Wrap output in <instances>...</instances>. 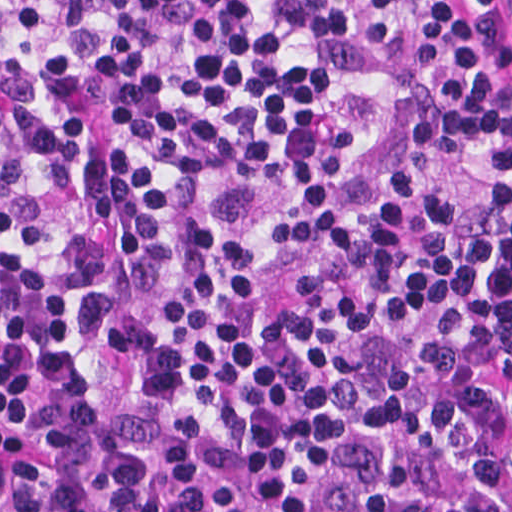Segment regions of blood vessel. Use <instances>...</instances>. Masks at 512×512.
Returning <instances> with one entry per match:
<instances>
[{"mask_svg": "<svg viewBox=\"0 0 512 512\" xmlns=\"http://www.w3.org/2000/svg\"><path fill=\"white\" fill-rule=\"evenodd\" d=\"M0 512H40L0 404Z\"/></svg>", "mask_w": 512, "mask_h": 512, "instance_id": "obj_1", "label": "blood vessel"}]
</instances>
